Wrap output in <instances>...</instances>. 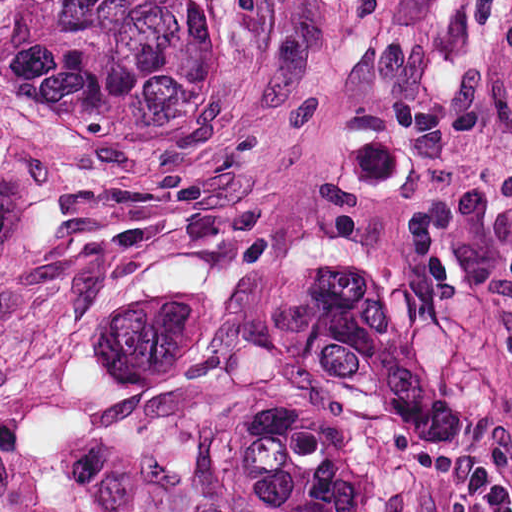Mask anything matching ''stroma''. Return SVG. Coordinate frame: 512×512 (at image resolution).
Wrapping results in <instances>:
<instances>
[{
    "label": "stroma",
    "instance_id": "1",
    "mask_svg": "<svg viewBox=\"0 0 512 512\" xmlns=\"http://www.w3.org/2000/svg\"><path fill=\"white\" fill-rule=\"evenodd\" d=\"M0 512H512V436L0 270Z\"/></svg>",
    "mask_w": 512,
    "mask_h": 512
}]
</instances>
